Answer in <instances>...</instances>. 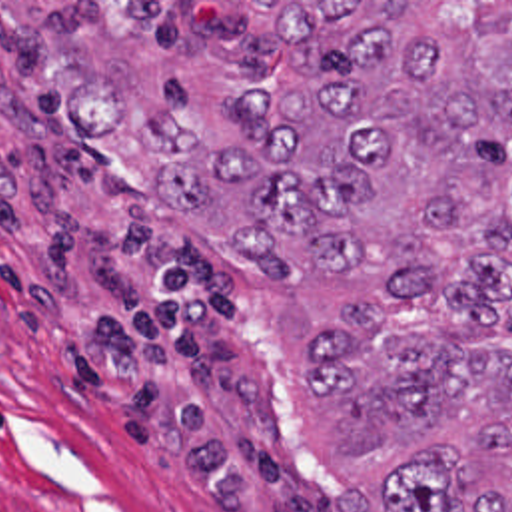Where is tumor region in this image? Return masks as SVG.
Segmentation results:
<instances>
[{
  "label": "tumor region",
  "instance_id": "obj_1",
  "mask_svg": "<svg viewBox=\"0 0 512 512\" xmlns=\"http://www.w3.org/2000/svg\"><path fill=\"white\" fill-rule=\"evenodd\" d=\"M269 6L211 138L125 82L55 108L257 275L315 512H512V2Z\"/></svg>",
  "mask_w": 512,
  "mask_h": 512
}]
</instances>
